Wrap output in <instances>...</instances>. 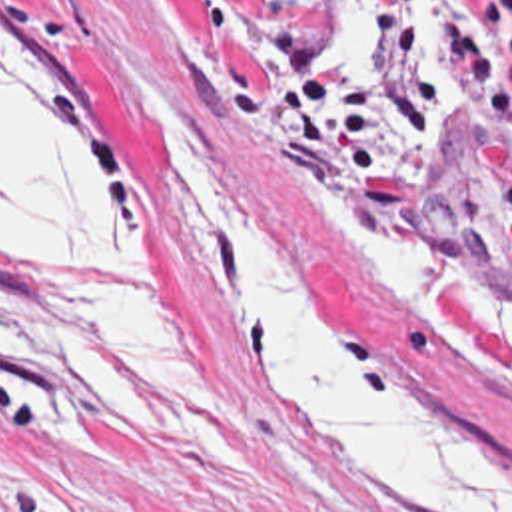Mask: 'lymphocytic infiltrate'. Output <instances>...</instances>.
I'll use <instances>...</instances> for the list:
<instances>
[{
  "label": "lymphocytic infiltrate",
  "mask_w": 512,
  "mask_h": 512,
  "mask_svg": "<svg viewBox=\"0 0 512 512\" xmlns=\"http://www.w3.org/2000/svg\"><path fill=\"white\" fill-rule=\"evenodd\" d=\"M376 17V47L386 73L378 79L334 77L317 61L311 35L279 15L275 101L289 133L313 149L326 169L344 171L378 151L388 123L406 131L432 125L458 95H468L512 123L506 73L482 47L448 21L444 35L454 49L452 73L428 79L424 59L430 35V0H368ZM510 0L466 3L468 21L512 57Z\"/></svg>",
  "instance_id": "1"
}]
</instances>
